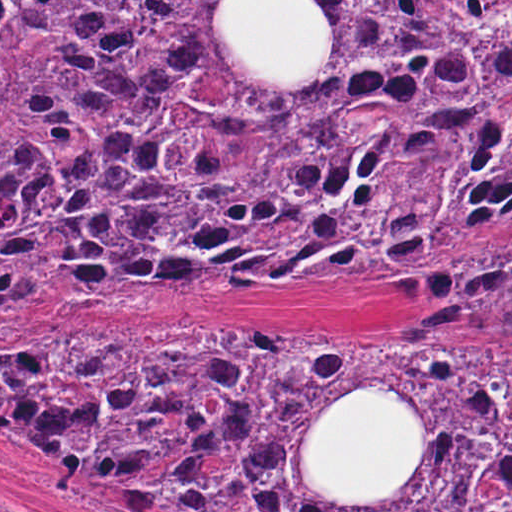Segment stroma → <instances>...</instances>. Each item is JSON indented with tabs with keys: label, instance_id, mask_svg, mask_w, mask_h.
<instances>
[{
	"label": "stroma",
	"instance_id": "1",
	"mask_svg": "<svg viewBox=\"0 0 512 512\" xmlns=\"http://www.w3.org/2000/svg\"><path fill=\"white\" fill-rule=\"evenodd\" d=\"M232 1L219 29L261 75H311L328 61V26L306 1L512 0H0ZM512 281V275L472 289ZM461 289L414 297L359 278L272 286L196 297L163 320H105L83 330H3L0 344L37 347L103 331L179 326H348L423 344H512L442 339L425 333L441 302ZM0 502L12 512H178L33 451L0 435Z\"/></svg>",
	"mask_w": 512,
	"mask_h": 512
}]
</instances>
